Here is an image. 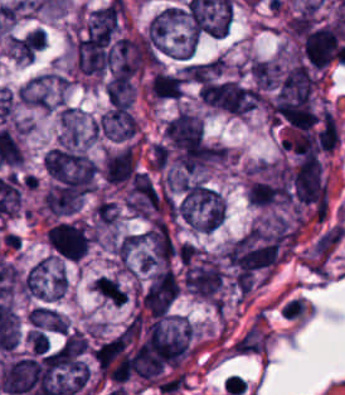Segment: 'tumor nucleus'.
I'll list each match as a JSON object with an SVG mask.
<instances>
[{"label": "tumor nucleus", "instance_id": "tumor-nucleus-1", "mask_svg": "<svg viewBox=\"0 0 345 395\" xmlns=\"http://www.w3.org/2000/svg\"><path fill=\"white\" fill-rule=\"evenodd\" d=\"M177 206L179 220L193 231H213L226 218L220 192L204 182H190L177 197Z\"/></svg>", "mask_w": 345, "mask_h": 395}, {"label": "tumor nucleus", "instance_id": "tumor-nucleus-2", "mask_svg": "<svg viewBox=\"0 0 345 395\" xmlns=\"http://www.w3.org/2000/svg\"><path fill=\"white\" fill-rule=\"evenodd\" d=\"M199 97L209 105L231 113L243 115L253 110V91L231 80H204Z\"/></svg>", "mask_w": 345, "mask_h": 395}, {"label": "tumor nucleus", "instance_id": "tumor-nucleus-3", "mask_svg": "<svg viewBox=\"0 0 345 395\" xmlns=\"http://www.w3.org/2000/svg\"><path fill=\"white\" fill-rule=\"evenodd\" d=\"M182 280L185 289L194 295L214 304H222L223 276L218 260L184 267Z\"/></svg>", "mask_w": 345, "mask_h": 395}, {"label": "tumor nucleus", "instance_id": "tumor-nucleus-4", "mask_svg": "<svg viewBox=\"0 0 345 395\" xmlns=\"http://www.w3.org/2000/svg\"><path fill=\"white\" fill-rule=\"evenodd\" d=\"M66 287L62 270L46 255L30 267L24 279V294L42 299L54 301Z\"/></svg>", "mask_w": 345, "mask_h": 395}, {"label": "tumor nucleus", "instance_id": "tumor-nucleus-5", "mask_svg": "<svg viewBox=\"0 0 345 395\" xmlns=\"http://www.w3.org/2000/svg\"><path fill=\"white\" fill-rule=\"evenodd\" d=\"M51 248L68 259H78L87 253L90 237L80 221H60L47 230Z\"/></svg>", "mask_w": 345, "mask_h": 395}, {"label": "tumor nucleus", "instance_id": "tumor-nucleus-6", "mask_svg": "<svg viewBox=\"0 0 345 395\" xmlns=\"http://www.w3.org/2000/svg\"><path fill=\"white\" fill-rule=\"evenodd\" d=\"M302 53L312 66H327L338 54V29L335 24L327 23L305 32Z\"/></svg>", "mask_w": 345, "mask_h": 395}, {"label": "tumor nucleus", "instance_id": "tumor-nucleus-7", "mask_svg": "<svg viewBox=\"0 0 345 395\" xmlns=\"http://www.w3.org/2000/svg\"><path fill=\"white\" fill-rule=\"evenodd\" d=\"M179 292V283L168 267L151 274L141 297V303L152 316L166 311Z\"/></svg>", "mask_w": 345, "mask_h": 395}, {"label": "tumor nucleus", "instance_id": "tumor-nucleus-8", "mask_svg": "<svg viewBox=\"0 0 345 395\" xmlns=\"http://www.w3.org/2000/svg\"><path fill=\"white\" fill-rule=\"evenodd\" d=\"M97 126L101 134L110 139L131 136L137 128V120L129 104L115 105L101 114Z\"/></svg>", "mask_w": 345, "mask_h": 395}, {"label": "tumor nucleus", "instance_id": "tumor-nucleus-9", "mask_svg": "<svg viewBox=\"0 0 345 395\" xmlns=\"http://www.w3.org/2000/svg\"><path fill=\"white\" fill-rule=\"evenodd\" d=\"M255 87L272 89L280 76V63L265 58H253L250 61Z\"/></svg>", "mask_w": 345, "mask_h": 395}, {"label": "tumor nucleus", "instance_id": "tumor-nucleus-10", "mask_svg": "<svg viewBox=\"0 0 345 395\" xmlns=\"http://www.w3.org/2000/svg\"><path fill=\"white\" fill-rule=\"evenodd\" d=\"M27 318L31 326L42 330L64 332V321L58 310L43 305H35L30 308Z\"/></svg>", "mask_w": 345, "mask_h": 395}, {"label": "tumor nucleus", "instance_id": "tumor-nucleus-11", "mask_svg": "<svg viewBox=\"0 0 345 395\" xmlns=\"http://www.w3.org/2000/svg\"><path fill=\"white\" fill-rule=\"evenodd\" d=\"M91 286L93 290L116 306L125 299V291L106 276H98L92 281Z\"/></svg>", "mask_w": 345, "mask_h": 395}]
</instances>
